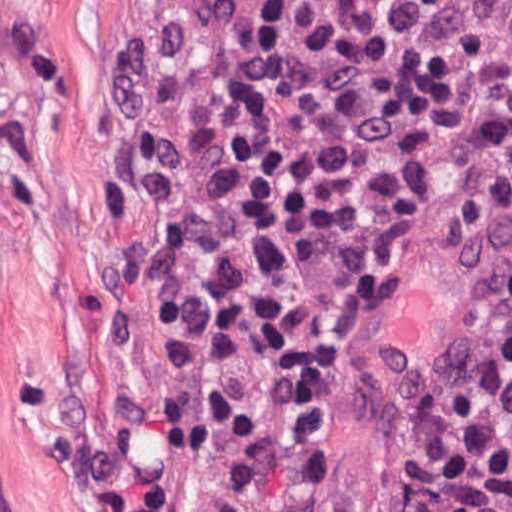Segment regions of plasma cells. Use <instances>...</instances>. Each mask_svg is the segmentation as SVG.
<instances>
[{
    "mask_svg": "<svg viewBox=\"0 0 512 512\" xmlns=\"http://www.w3.org/2000/svg\"><path fill=\"white\" fill-rule=\"evenodd\" d=\"M453 109L470 165L445 206L460 231L512 235V0H466L456 27Z\"/></svg>",
    "mask_w": 512,
    "mask_h": 512,
    "instance_id": "9512152a",
    "label": "plasma cells"
}]
</instances>
